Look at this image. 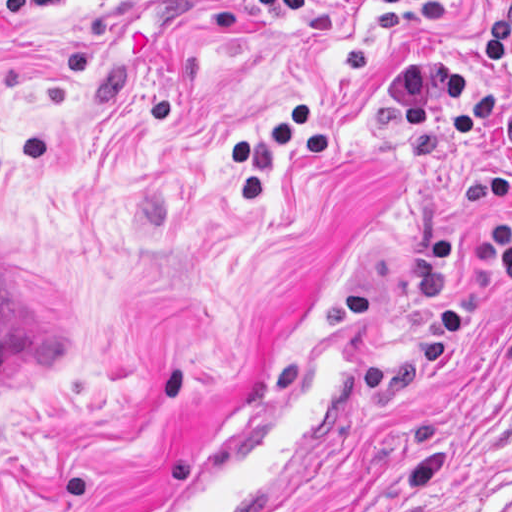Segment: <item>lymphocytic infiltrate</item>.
I'll list each match as a JSON object with an SVG mask.
<instances>
[{"label":"lymphocytic infiltrate","instance_id":"f902f5d3","mask_svg":"<svg viewBox=\"0 0 512 512\" xmlns=\"http://www.w3.org/2000/svg\"><path fill=\"white\" fill-rule=\"evenodd\" d=\"M337 1L374 3L347 42L342 76L295 104L266 112L249 134L223 141V161L247 204L263 201L268 174L281 159L316 162L335 150L349 96L373 55L395 33L414 23L444 18L459 4L458 0ZM482 53L490 65L509 59L512 0L501 5L483 36ZM386 92L392 107L401 112L407 139L427 143L435 127H445L452 135L478 129L503 153V165L497 171L471 173L463 179V198L471 206L503 210L498 229L487 236L438 235L418 253L421 262H463L468 268L460 295L432 319L436 341L454 340L483 295L512 286V101L471 77L458 54L404 62L392 72Z\"/></svg>","mask_w":512,"mask_h":512}]
</instances>
